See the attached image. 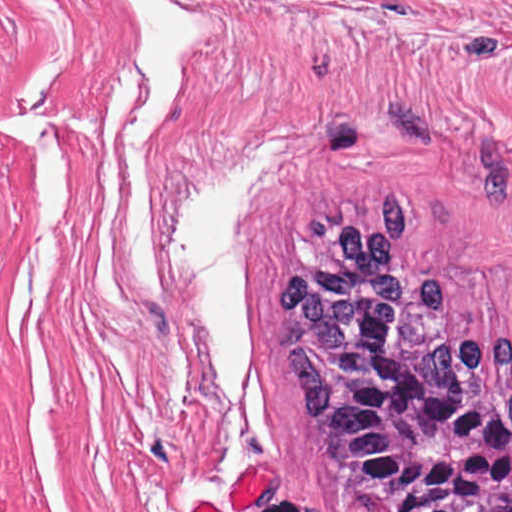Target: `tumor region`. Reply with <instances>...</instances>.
Instances as JSON below:
<instances>
[{
  "mask_svg": "<svg viewBox=\"0 0 512 512\" xmlns=\"http://www.w3.org/2000/svg\"><path fill=\"white\" fill-rule=\"evenodd\" d=\"M359 189L283 230L272 337L340 487L372 512H512V335H467Z\"/></svg>",
  "mask_w": 512,
  "mask_h": 512,
  "instance_id": "e687c5a6",
  "label": "tumor region"
}]
</instances>
